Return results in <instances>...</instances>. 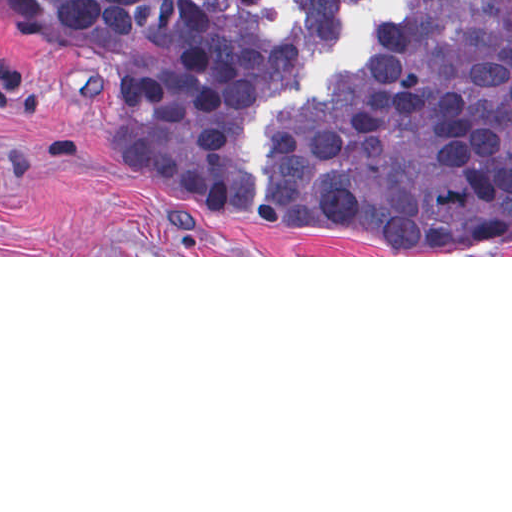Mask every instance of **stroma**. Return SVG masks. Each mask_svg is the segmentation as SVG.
Masks as SVG:
<instances>
[{"label":"stroma","instance_id":"stroma-1","mask_svg":"<svg viewBox=\"0 0 512 512\" xmlns=\"http://www.w3.org/2000/svg\"><path fill=\"white\" fill-rule=\"evenodd\" d=\"M0 257L376 255L342 240L244 231L141 193L102 137L62 41L0 4Z\"/></svg>","mask_w":512,"mask_h":512}]
</instances>
